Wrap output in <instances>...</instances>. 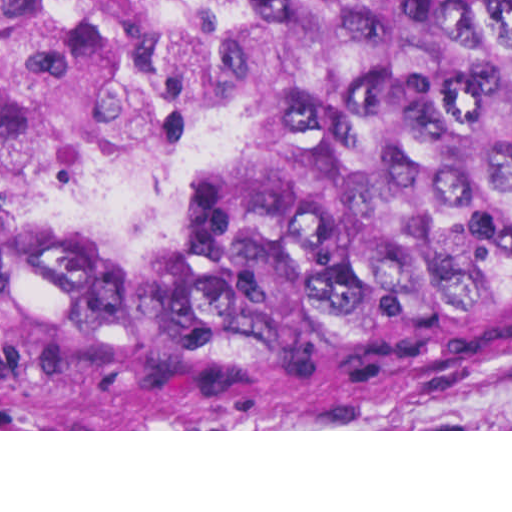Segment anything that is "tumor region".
Wrapping results in <instances>:
<instances>
[{
  "instance_id": "e687c5a6",
  "label": "tumor region",
  "mask_w": 512,
  "mask_h": 512,
  "mask_svg": "<svg viewBox=\"0 0 512 512\" xmlns=\"http://www.w3.org/2000/svg\"><path fill=\"white\" fill-rule=\"evenodd\" d=\"M263 158L178 227L9 226L0 412L57 429L410 418L512 382V0H232Z\"/></svg>"
}]
</instances>
